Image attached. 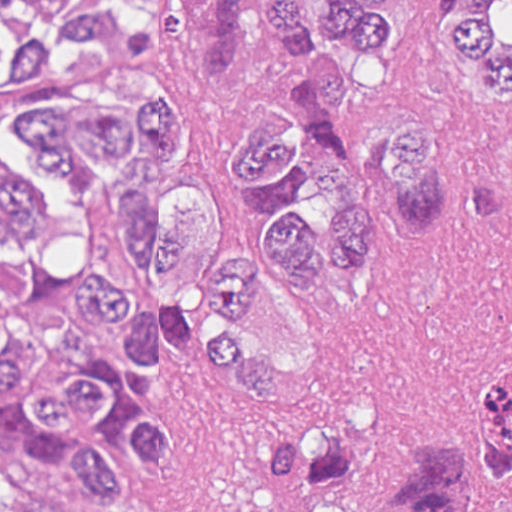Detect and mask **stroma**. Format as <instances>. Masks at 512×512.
<instances>
[{
	"label": "stroma",
	"instance_id": "obj_1",
	"mask_svg": "<svg viewBox=\"0 0 512 512\" xmlns=\"http://www.w3.org/2000/svg\"><path fill=\"white\" fill-rule=\"evenodd\" d=\"M290 44L264 30L255 0L249 37L231 73L208 79L182 52L175 0H160V55L138 108L168 101L186 135L175 168H154L153 197L180 177L214 195L224 250L257 237L259 223L223 169V148L254 101H273ZM0 108V161L75 215L70 180L38 166L28 138ZM446 122V221L439 233L396 238L382 228L375 254L298 302L264 264L257 301L232 318L256 350L286 370L272 401L243 399L193 344L159 336V357L131 381L142 416L169 427L175 463L108 444L131 476V498L96 503L78 491L75 463L30 470L0 458V512H220L232 477L256 445L283 432L339 427L413 448L479 416L485 394L512 371V114L488 109L441 22V0H392L390 34L342 129L361 169L396 160L412 126ZM307 144L315 148L312 137ZM333 211L317 189L296 213L326 229ZM2 243L0 242V252ZM488 511L512 512L488 484Z\"/></svg>",
	"mask_w": 512,
	"mask_h": 512
}]
</instances>
